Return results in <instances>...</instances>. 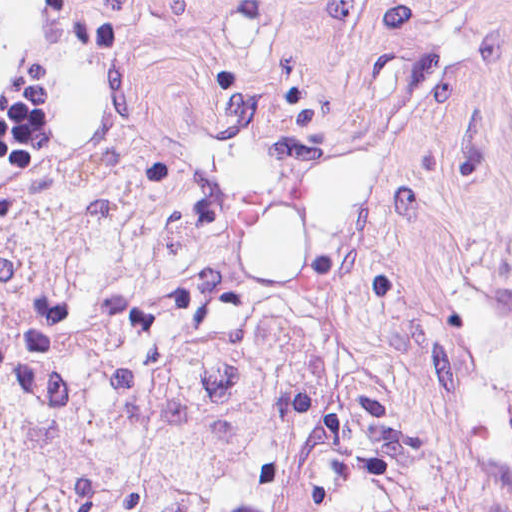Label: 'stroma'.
<instances>
[{"label": "stroma", "instance_id": "stroma-1", "mask_svg": "<svg viewBox=\"0 0 512 512\" xmlns=\"http://www.w3.org/2000/svg\"><path fill=\"white\" fill-rule=\"evenodd\" d=\"M142 115L222 184L427 247L512 209V0H0V208L104 185Z\"/></svg>", "mask_w": 512, "mask_h": 512}]
</instances>
